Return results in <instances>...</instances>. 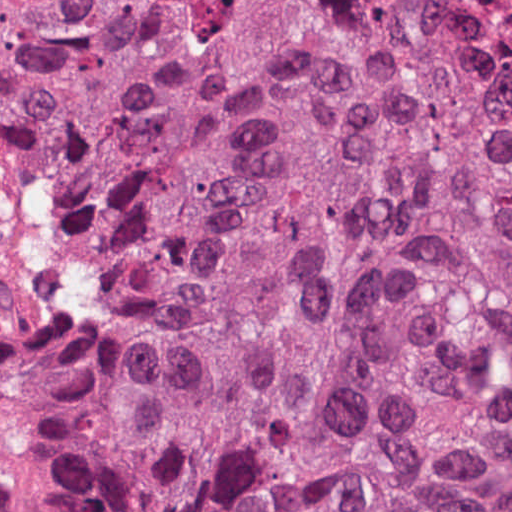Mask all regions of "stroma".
<instances>
[{
    "label": "stroma",
    "instance_id": "35a3bbf8",
    "mask_svg": "<svg viewBox=\"0 0 512 512\" xmlns=\"http://www.w3.org/2000/svg\"><path fill=\"white\" fill-rule=\"evenodd\" d=\"M0 512H50L27 455L0 443Z\"/></svg>",
    "mask_w": 512,
    "mask_h": 512
}]
</instances>
